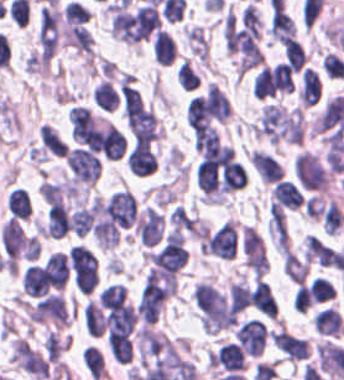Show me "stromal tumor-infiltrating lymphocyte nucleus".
<instances>
[{"label":"stromal tumor-infiltrating lymphocyte nucleus","instance_id":"23","mask_svg":"<svg viewBox=\"0 0 344 380\" xmlns=\"http://www.w3.org/2000/svg\"><path fill=\"white\" fill-rule=\"evenodd\" d=\"M49 283L43 266L29 265L21 278V288L24 293L34 297L46 295Z\"/></svg>","mask_w":344,"mask_h":380},{"label":"stromal tumor-infiltrating lymphocyte nucleus","instance_id":"51","mask_svg":"<svg viewBox=\"0 0 344 380\" xmlns=\"http://www.w3.org/2000/svg\"><path fill=\"white\" fill-rule=\"evenodd\" d=\"M310 291L314 302L332 299L333 287L325 277H317L310 282Z\"/></svg>","mask_w":344,"mask_h":380},{"label":"stromal tumor-infiltrating lymphocyte nucleus","instance_id":"11","mask_svg":"<svg viewBox=\"0 0 344 380\" xmlns=\"http://www.w3.org/2000/svg\"><path fill=\"white\" fill-rule=\"evenodd\" d=\"M29 319L57 325L68 323L67 309L61 294L49 293L29 310Z\"/></svg>","mask_w":344,"mask_h":380},{"label":"stromal tumor-infiltrating lymphocyte nucleus","instance_id":"39","mask_svg":"<svg viewBox=\"0 0 344 380\" xmlns=\"http://www.w3.org/2000/svg\"><path fill=\"white\" fill-rule=\"evenodd\" d=\"M309 263L285 248L283 256V273L295 281L300 283L306 274Z\"/></svg>","mask_w":344,"mask_h":380},{"label":"stromal tumor-infiltrating lymphocyte nucleus","instance_id":"17","mask_svg":"<svg viewBox=\"0 0 344 380\" xmlns=\"http://www.w3.org/2000/svg\"><path fill=\"white\" fill-rule=\"evenodd\" d=\"M238 342L248 354L260 355L264 350L265 326L259 319L243 322L237 329Z\"/></svg>","mask_w":344,"mask_h":380},{"label":"stromal tumor-infiltrating lymphocyte nucleus","instance_id":"26","mask_svg":"<svg viewBox=\"0 0 344 380\" xmlns=\"http://www.w3.org/2000/svg\"><path fill=\"white\" fill-rule=\"evenodd\" d=\"M249 303L262 315L276 316V303L270 288L258 278L249 293Z\"/></svg>","mask_w":344,"mask_h":380},{"label":"stromal tumor-infiltrating lymphocyte nucleus","instance_id":"2","mask_svg":"<svg viewBox=\"0 0 344 380\" xmlns=\"http://www.w3.org/2000/svg\"><path fill=\"white\" fill-rule=\"evenodd\" d=\"M273 142H300L302 120L298 108L267 103L252 130Z\"/></svg>","mask_w":344,"mask_h":380},{"label":"stromal tumor-infiltrating lymphocyte nucleus","instance_id":"55","mask_svg":"<svg viewBox=\"0 0 344 380\" xmlns=\"http://www.w3.org/2000/svg\"><path fill=\"white\" fill-rule=\"evenodd\" d=\"M312 301L310 286L298 284L293 298L294 306L302 313Z\"/></svg>","mask_w":344,"mask_h":380},{"label":"stromal tumor-infiltrating lymphocyte nucleus","instance_id":"25","mask_svg":"<svg viewBox=\"0 0 344 380\" xmlns=\"http://www.w3.org/2000/svg\"><path fill=\"white\" fill-rule=\"evenodd\" d=\"M270 196L284 209H298L302 204V195L294 183L279 179L274 183Z\"/></svg>","mask_w":344,"mask_h":380},{"label":"stromal tumor-infiltrating lymphocyte nucleus","instance_id":"34","mask_svg":"<svg viewBox=\"0 0 344 380\" xmlns=\"http://www.w3.org/2000/svg\"><path fill=\"white\" fill-rule=\"evenodd\" d=\"M247 181V174L239 162L228 160L221 173L223 190H235L243 187Z\"/></svg>","mask_w":344,"mask_h":380},{"label":"stromal tumor-infiltrating lymphocyte nucleus","instance_id":"50","mask_svg":"<svg viewBox=\"0 0 344 380\" xmlns=\"http://www.w3.org/2000/svg\"><path fill=\"white\" fill-rule=\"evenodd\" d=\"M250 288L247 283H233L230 290L231 306L239 313L243 310L249 300Z\"/></svg>","mask_w":344,"mask_h":380},{"label":"stromal tumor-infiltrating lymphocyte nucleus","instance_id":"36","mask_svg":"<svg viewBox=\"0 0 344 380\" xmlns=\"http://www.w3.org/2000/svg\"><path fill=\"white\" fill-rule=\"evenodd\" d=\"M107 346L118 364H126L130 360L131 345L128 335L109 332Z\"/></svg>","mask_w":344,"mask_h":380},{"label":"stromal tumor-infiltrating lymphocyte nucleus","instance_id":"27","mask_svg":"<svg viewBox=\"0 0 344 380\" xmlns=\"http://www.w3.org/2000/svg\"><path fill=\"white\" fill-rule=\"evenodd\" d=\"M335 250L315 235L305 239L304 255L306 261L324 266H332Z\"/></svg>","mask_w":344,"mask_h":380},{"label":"stromal tumor-infiltrating lymphocyte nucleus","instance_id":"47","mask_svg":"<svg viewBox=\"0 0 344 380\" xmlns=\"http://www.w3.org/2000/svg\"><path fill=\"white\" fill-rule=\"evenodd\" d=\"M83 322L88 334L93 336L102 334L104 323L95 305L89 301L85 305Z\"/></svg>","mask_w":344,"mask_h":380},{"label":"stromal tumor-infiltrating lymphocyte nucleus","instance_id":"18","mask_svg":"<svg viewBox=\"0 0 344 380\" xmlns=\"http://www.w3.org/2000/svg\"><path fill=\"white\" fill-rule=\"evenodd\" d=\"M276 348L289 360H298L309 355V347L304 338L285 330L272 333Z\"/></svg>","mask_w":344,"mask_h":380},{"label":"stromal tumor-infiltrating lymphocyte nucleus","instance_id":"45","mask_svg":"<svg viewBox=\"0 0 344 380\" xmlns=\"http://www.w3.org/2000/svg\"><path fill=\"white\" fill-rule=\"evenodd\" d=\"M173 227L190 235L197 236L195 219L182 206H175L169 218Z\"/></svg>","mask_w":344,"mask_h":380},{"label":"stromal tumor-infiltrating lymphocyte nucleus","instance_id":"30","mask_svg":"<svg viewBox=\"0 0 344 380\" xmlns=\"http://www.w3.org/2000/svg\"><path fill=\"white\" fill-rule=\"evenodd\" d=\"M186 120L191 131L206 127L209 122V112L206 96H192L186 106Z\"/></svg>","mask_w":344,"mask_h":380},{"label":"stromal tumor-infiltrating lymphocyte nucleus","instance_id":"7","mask_svg":"<svg viewBox=\"0 0 344 380\" xmlns=\"http://www.w3.org/2000/svg\"><path fill=\"white\" fill-rule=\"evenodd\" d=\"M1 239L6 256L33 261L37 254L35 236L16 219H9L2 227Z\"/></svg>","mask_w":344,"mask_h":380},{"label":"stromal tumor-infiltrating lymphocyte nucleus","instance_id":"41","mask_svg":"<svg viewBox=\"0 0 344 380\" xmlns=\"http://www.w3.org/2000/svg\"><path fill=\"white\" fill-rule=\"evenodd\" d=\"M6 205L14 218H27L30 211V199L25 190L14 188L6 198Z\"/></svg>","mask_w":344,"mask_h":380},{"label":"stromal tumor-infiltrating lymphocyte nucleus","instance_id":"12","mask_svg":"<svg viewBox=\"0 0 344 380\" xmlns=\"http://www.w3.org/2000/svg\"><path fill=\"white\" fill-rule=\"evenodd\" d=\"M58 27L59 13L42 7L37 27L41 61H48L56 49Z\"/></svg>","mask_w":344,"mask_h":380},{"label":"stromal tumor-infiltrating lymphocyte nucleus","instance_id":"52","mask_svg":"<svg viewBox=\"0 0 344 380\" xmlns=\"http://www.w3.org/2000/svg\"><path fill=\"white\" fill-rule=\"evenodd\" d=\"M177 82L187 91L200 83L198 75L185 60L177 70Z\"/></svg>","mask_w":344,"mask_h":380},{"label":"stromal tumor-infiltrating lymphocyte nucleus","instance_id":"43","mask_svg":"<svg viewBox=\"0 0 344 380\" xmlns=\"http://www.w3.org/2000/svg\"><path fill=\"white\" fill-rule=\"evenodd\" d=\"M244 261L251 271L259 278L268 268V262L262 247H245Z\"/></svg>","mask_w":344,"mask_h":380},{"label":"stromal tumor-infiltrating lymphocyte nucleus","instance_id":"19","mask_svg":"<svg viewBox=\"0 0 344 380\" xmlns=\"http://www.w3.org/2000/svg\"><path fill=\"white\" fill-rule=\"evenodd\" d=\"M211 366L233 372L244 368V354L240 345L231 341L221 345L212 355Z\"/></svg>","mask_w":344,"mask_h":380},{"label":"stromal tumor-infiltrating lymphocyte nucleus","instance_id":"4","mask_svg":"<svg viewBox=\"0 0 344 380\" xmlns=\"http://www.w3.org/2000/svg\"><path fill=\"white\" fill-rule=\"evenodd\" d=\"M61 37L65 45L90 52L92 35L88 12L75 2H69L62 12Z\"/></svg>","mask_w":344,"mask_h":380},{"label":"stromal tumor-infiltrating lymphocyte nucleus","instance_id":"37","mask_svg":"<svg viewBox=\"0 0 344 380\" xmlns=\"http://www.w3.org/2000/svg\"><path fill=\"white\" fill-rule=\"evenodd\" d=\"M81 360L91 380H100L105 376L103 358L98 349L89 345L81 351Z\"/></svg>","mask_w":344,"mask_h":380},{"label":"stromal tumor-infiltrating lymphocyte nucleus","instance_id":"46","mask_svg":"<svg viewBox=\"0 0 344 380\" xmlns=\"http://www.w3.org/2000/svg\"><path fill=\"white\" fill-rule=\"evenodd\" d=\"M68 183L64 181H43L41 182L37 192L45 202L56 203L62 199Z\"/></svg>","mask_w":344,"mask_h":380},{"label":"stromal tumor-infiltrating lymphocyte nucleus","instance_id":"33","mask_svg":"<svg viewBox=\"0 0 344 380\" xmlns=\"http://www.w3.org/2000/svg\"><path fill=\"white\" fill-rule=\"evenodd\" d=\"M153 54L157 64L165 66L176 56L174 40L160 28L154 34Z\"/></svg>","mask_w":344,"mask_h":380},{"label":"stromal tumor-infiltrating lymphocyte nucleus","instance_id":"54","mask_svg":"<svg viewBox=\"0 0 344 380\" xmlns=\"http://www.w3.org/2000/svg\"><path fill=\"white\" fill-rule=\"evenodd\" d=\"M65 344L66 343L61 338L50 330L47 334L44 346L46 359L56 362Z\"/></svg>","mask_w":344,"mask_h":380},{"label":"stromal tumor-infiltrating lymphocyte nucleus","instance_id":"31","mask_svg":"<svg viewBox=\"0 0 344 380\" xmlns=\"http://www.w3.org/2000/svg\"><path fill=\"white\" fill-rule=\"evenodd\" d=\"M46 268L50 284L55 289H63L68 279L67 257L62 252H55L47 257Z\"/></svg>","mask_w":344,"mask_h":380},{"label":"stromal tumor-infiltrating lymphocyte nucleus","instance_id":"38","mask_svg":"<svg viewBox=\"0 0 344 380\" xmlns=\"http://www.w3.org/2000/svg\"><path fill=\"white\" fill-rule=\"evenodd\" d=\"M40 141L43 147L52 154H66L67 143L50 123H42Z\"/></svg>","mask_w":344,"mask_h":380},{"label":"stromal tumor-infiltrating lymphocyte nucleus","instance_id":"1","mask_svg":"<svg viewBox=\"0 0 344 380\" xmlns=\"http://www.w3.org/2000/svg\"><path fill=\"white\" fill-rule=\"evenodd\" d=\"M223 27L227 51L239 72L263 63L260 17L253 5L228 12Z\"/></svg>","mask_w":344,"mask_h":380},{"label":"stromal tumor-infiltrating lymphocyte nucleus","instance_id":"53","mask_svg":"<svg viewBox=\"0 0 344 380\" xmlns=\"http://www.w3.org/2000/svg\"><path fill=\"white\" fill-rule=\"evenodd\" d=\"M242 246L249 249L264 250V239L252 225H244L242 230Z\"/></svg>","mask_w":344,"mask_h":380},{"label":"stromal tumor-infiltrating lymphocyte nucleus","instance_id":"13","mask_svg":"<svg viewBox=\"0 0 344 380\" xmlns=\"http://www.w3.org/2000/svg\"><path fill=\"white\" fill-rule=\"evenodd\" d=\"M11 360L31 375L48 377L47 364L44 357L28 343L14 339Z\"/></svg>","mask_w":344,"mask_h":380},{"label":"stromal tumor-infiltrating lymphocyte nucleus","instance_id":"10","mask_svg":"<svg viewBox=\"0 0 344 380\" xmlns=\"http://www.w3.org/2000/svg\"><path fill=\"white\" fill-rule=\"evenodd\" d=\"M76 184H93L100 173L97 157L84 148H71L65 156Z\"/></svg>","mask_w":344,"mask_h":380},{"label":"stromal tumor-infiltrating lymphocyte nucleus","instance_id":"8","mask_svg":"<svg viewBox=\"0 0 344 380\" xmlns=\"http://www.w3.org/2000/svg\"><path fill=\"white\" fill-rule=\"evenodd\" d=\"M292 88L291 69L280 61L261 70L254 81L253 93L264 98L289 92Z\"/></svg>","mask_w":344,"mask_h":380},{"label":"stromal tumor-infiltrating lymphocyte nucleus","instance_id":"6","mask_svg":"<svg viewBox=\"0 0 344 380\" xmlns=\"http://www.w3.org/2000/svg\"><path fill=\"white\" fill-rule=\"evenodd\" d=\"M177 289L175 271L150 269L146 274L138 299V310L156 311Z\"/></svg>","mask_w":344,"mask_h":380},{"label":"stromal tumor-infiltrating lymphocyte nucleus","instance_id":"9","mask_svg":"<svg viewBox=\"0 0 344 380\" xmlns=\"http://www.w3.org/2000/svg\"><path fill=\"white\" fill-rule=\"evenodd\" d=\"M294 171L296 180L304 190L325 191V169L320 160L309 152H301L295 157Z\"/></svg>","mask_w":344,"mask_h":380},{"label":"stromal tumor-infiltrating lymphocyte nucleus","instance_id":"48","mask_svg":"<svg viewBox=\"0 0 344 380\" xmlns=\"http://www.w3.org/2000/svg\"><path fill=\"white\" fill-rule=\"evenodd\" d=\"M323 224L329 235H336L343 225V216L337 203L333 200L323 214Z\"/></svg>","mask_w":344,"mask_h":380},{"label":"stromal tumor-infiltrating lymphocyte nucleus","instance_id":"28","mask_svg":"<svg viewBox=\"0 0 344 380\" xmlns=\"http://www.w3.org/2000/svg\"><path fill=\"white\" fill-rule=\"evenodd\" d=\"M267 232L277 248H288L284 211L271 203L268 208Z\"/></svg>","mask_w":344,"mask_h":380},{"label":"stromal tumor-infiltrating lymphocyte nucleus","instance_id":"29","mask_svg":"<svg viewBox=\"0 0 344 380\" xmlns=\"http://www.w3.org/2000/svg\"><path fill=\"white\" fill-rule=\"evenodd\" d=\"M315 331L323 335H339L344 331V322L338 311L325 307L314 318Z\"/></svg>","mask_w":344,"mask_h":380},{"label":"stromal tumor-infiltrating lymphocyte nucleus","instance_id":"21","mask_svg":"<svg viewBox=\"0 0 344 380\" xmlns=\"http://www.w3.org/2000/svg\"><path fill=\"white\" fill-rule=\"evenodd\" d=\"M102 155L109 160L121 157L126 149V141L118 128L111 123H106L99 132Z\"/></svg>","mask_w":344,"mask_h":380},{"label":"stromal tumor-infiltrating lymphocyte nucleus","instance_id":"42","mask_svg":"<svg viewBox=\"0 0 344 380\" xmlns=\"http://www.w3.org/2000/svg\"><path fill=\"white\" fill-rule=\"evenodd\" d=\"M126 288L118 283L108 284L98 297L99 306L107 309H120L124 298Z\"/></svg>","mask_w":344,"mask_h":380},{"label":"stromal tumor-infiltrating lymphocyte nucleus","instance_id":"16","mask_svg":"<svg viewBox=\"0 0 344 380\" xmlns=\"http://www.w3.org/2000/svg\"><path fill=\"white\" fill-rule=\"evenodd\" d=\"M68 120L73 139L87 144L97 129L90 108L82 105L70 107Z\"/></svg>","mask_w":344,"mask_h":380},{"label":"stromal tumor-infiltrating lymphocyte nucleus","instance_id":"24","mask_svg":"<svg viewBox=\"0 0 344 380\" xmlns=\"http://www.w3.org/2000/svg\"><path fill=\"white\" fill-rule=\"evenodd\" d=\"M248 157L261 181L275 182L281 178V166L278 160L268 153L253 149Z\"/></svg>","mask_w":344,"mask_h":380},{"label":"stromal tumor-infiltrating lymphocyte nucleus","instance_id":"49","mask_svg":"<svg viewBox=\"0 0 344 380\" xmlns=\"http://www.w3.org/2000/svg\"><path fill=\"white\" fill-rule=\"evenodd\" d=\"M285 60L293 70L301 69L305 61V51L301 44L295 39L288 41L284 48Z\"/></svg>","mask_w":344,"mask_h":380},{"label":"stromal tumor-infiltrating lymphocyte nucleus","instance_id":"14","mask_svg":"<svg viewBox=\"0 0 344 380\" xmlns=\"http://www.w3.org/2000/svg\"><path fill=\"white\" fill-rule=\"evenodd\" d=\"M237 231L227 220L222 222L207 239L210 254L223 259H232L236 254Z\"/></svg>","mask_w":344,"mask_h":380},{"label":"stromal tumor-infiltrating lymphocyte nucleus","instance_id":"32","mask_svg":"<svg viewBox=\"0 0 344 380\" xmlns=\"http://www.w3.org/2000/svg\"><path fill=\"white\" fill-rule=\"evenodd\" d=\"M321 86L317 74L305 67L301 72L299 97L301 104L310 106L320 98Z\"/></svg>","mask_w":344,"mask_h":380},{"label":"stromal tumor-infiltrating lymphocyte nucleus","instance_id":"44","mask_svg":"<svg viewBox=\"0 0 344 380\" xmlns=\"http://www.w3.org/2000/svg\"><path fill=\"white\" fill-rule=\"evenodd\" d=\"M218 140V132L212 126L201 124L194 128V148L198 152L213 148Z\"/></svg>","mask_w":344,"mask_h":380},{"label":"stromal tumor-infiltrating lymphocyte nucleus","instance_id":"3","mask_svg":"<svg viewBox=\"0 0 344 380\" xmlns=\"http://www.w3.org/2000/svg\"><path fill=\"white\" fill-rule=\"evenodd\" d=\"M194 301L207 334H217L234 323V314L226 298L208 284L199 283L194 288Z\"/></svg>","mask_w":344,"mask_h":380},{"label":"stromal tumor-infiltrating lymphocyte nucleus","instance_id":"22","mask_svg":"<svg viewBox=\"0 0 344 380\" xmlns=\"http://www.w3.org/2000/svg\"><path fill=\"white\" fill-rule=\"evenodd\" d=\"M129 170L135 175L152 173L156 168L155 153L143 143H135L128 153Z\"/></svg>","mask_w":344,"mask_h":380},{"label":"stromal tumor-infiltrating lymphocyte nucleus","instance_id":"15","mask_svg":"<svg viewBox=\"0 0 344 380\" xmlns=\"http://www.w3.org/2000/svg\"><path fill=\"white\" fill-rule=\"evenodd\" d=\"M134 230L144 246H152L162 239V219L154 208L145 207L134 224Z\"/></svg>","mask_w":344,"mask_h":380},{"label":"stromal tumor-infiltrating lymphocyte nucleus","instance_id":"35","mask_svg":"<svg viewBox=\"0 0 344 380\" xmlns=\"http://www.w3.org/2000/svg\"><path fill=\"white\" fill-rule=\"evenodd\" d=\"M207 98L211 118L224 122L231 111L227 98L218 86L211 84L207 87Z\"/></svg>","mask_w":344,"mask_h":380},{"label":"stromal tumor-infiltrating lymphocyte nucleus","instance_id":"20","mask_svg":"<svg viewBox=\"0 0 344 380\" xmlns=\"http://www.w3.org/2000/svg\"><path fill=\"white\" fill-rule=\"evenodd\" d=\"M71 230L67 208L64 202L50 204L46 211L45 236L61 238Z\"/></svg>","mask_w":344,"mask_h":380},{"label":"stromal tumor-infiltrating lymphocyte nucleus","instance_id":"40","mask_svg":"<svg viewBox=\"0 0 344 380\" xmlns=\"http://www.w3.org/2000/svg\"><path fill=\"white\" fill-rule=\"evenodd\" d=\"M93 103L106 111H114L119 104V98L108 81H101L93 91Z\"/></svg>","mask_w":344,"mask_h":380},{"label":"stromal tumor-infiltrating lymphocyte nucleus","instance_id":"5","mask_svg":"<svg viewBox=\"0 0 344 380\" xmlns=\"http://www.w3.org/2000/svg\"><path fill=\"white\" fill-rule=\"evenodd\" d=\"M123 113L135 142H149L157 130L151 112L138 91L123 92Z\"/></svg>","mask_w":344,"mask_h":380}]
</instances>
